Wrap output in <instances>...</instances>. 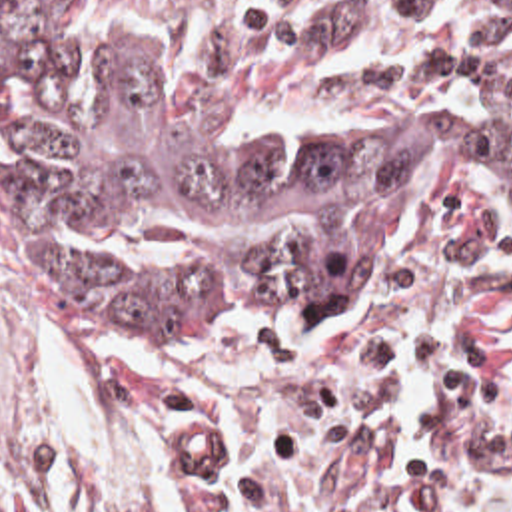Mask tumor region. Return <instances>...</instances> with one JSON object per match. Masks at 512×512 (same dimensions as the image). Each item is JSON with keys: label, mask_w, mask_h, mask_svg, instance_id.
Here are the masks:
<instances>
[{"label": "tumor region", "mask_w": 512, "mask_h": 512, "mask_svg": "<svg viewBox=\"0 0 512 512\" xmlns=\"http://www.w3.org/2000/svg\"><path fill=\"white\" fill-rule=\"evenodd\" d=\"M429 189L512 229V135L385 111L230 119L108 0H0V269L62 327L335 325ZM0 512H38L2 451Z\"/></svg>", "instance_id": "e687c5a6"}]
</instances>
